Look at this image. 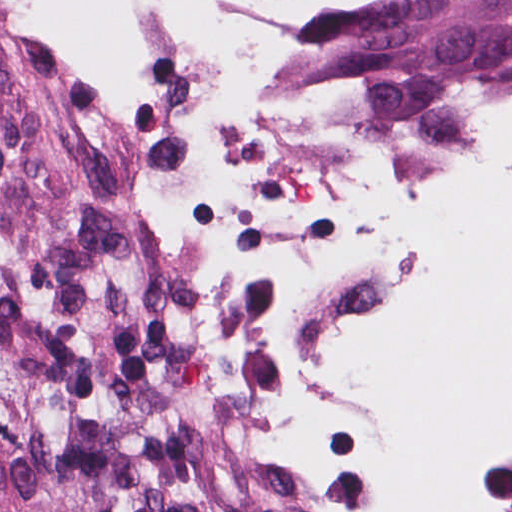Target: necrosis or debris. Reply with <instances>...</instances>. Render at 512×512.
I'll return each instance as SVG.
<instances>
[{
    "label": "necrosis or debris",
    "instance_id": "necrosis-or-debris-1",
    "mask_svg": "<svg viewBox=\"0 0 512 512\" xmlns=\"http://www.w3.org/2000/svg\"><path fill=\"white\" fill-rule=\"evenodd\" d=\"M49 170L228 319L286 512H512V54L63 76Z\"/></svg>",
    "mask_w": 512,
    "mask_h": 512
}]
</instances>
